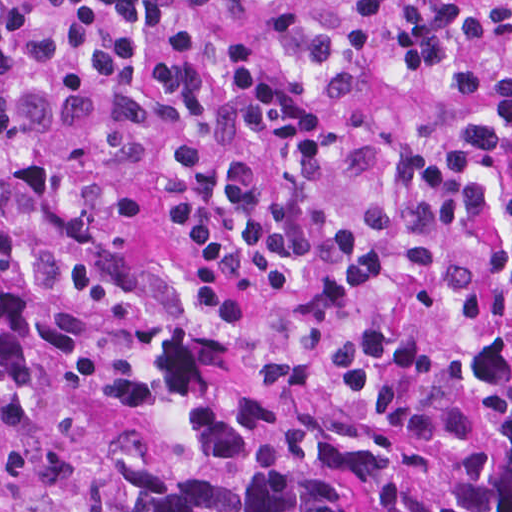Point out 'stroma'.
<instances>
[{
    "label": "stroma",
    "instance_id": "35a3bbf8",
    "mask_svg": "<svg viewBox=\"0 0 512 512\" xmlns=\"http://www.w3.org/2000/svg\"><path fill=\"white\" fill-rule=\"evenodd\" d=\"M0 228L36 262L62 272L98 295L108 297L71 253L30 237L17 213L0 210Z\"/></svg>",
    "mask_w": 512,
    "mask_h": 512
}]
</instances>
